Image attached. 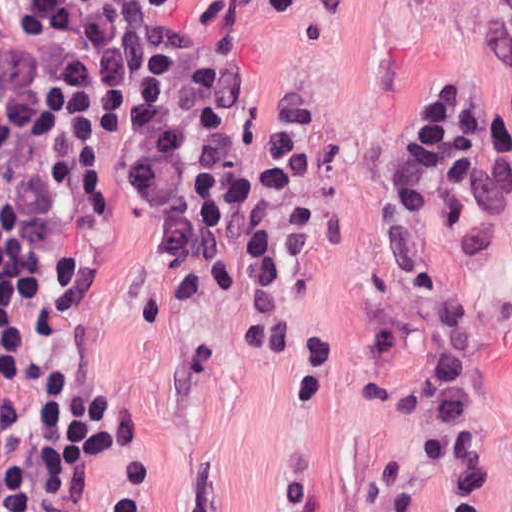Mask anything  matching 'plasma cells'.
I'll list each match as a JSON object with an SVG mask.
<instances>
[{
  "instance_id": "obj_1",
  "label": "plasma cells",
  "mask_w": 512,
  "mask_h": 512,
  "mask_svg": "<svg viewBox=\"0 0 512 512\" xmlns=\"http://www.w3.org/2000/svg\"><path fill=\"white\" fill-rule=\"evenodd\" d=\"M476 15L475 50L488 68L512 69V0H441ZM399 338L419 340L424 364L408 384H368L362 400L415 435V449L443 512H489L490 458L482 405L484 347L478 329L457 298L429 310L391 319L372 330V351L393 348ZM386 494L380 511L419 512L417 485L398 460L375 465Z\"/></svg>"
}]
</instances>
